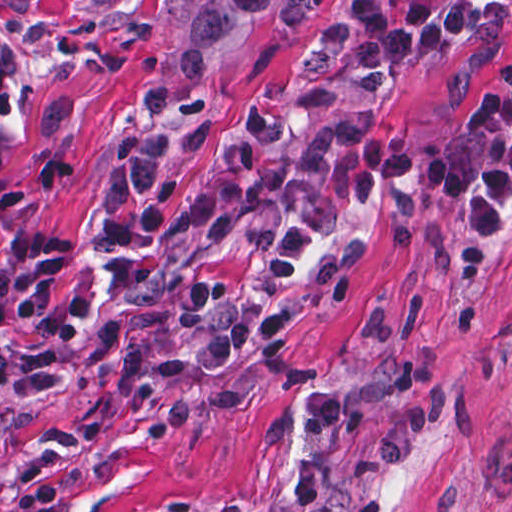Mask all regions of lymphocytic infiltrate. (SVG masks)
Returning <instances> with one entry per match:
<instances>
[{"instance_id":"f902f5d3","label":"lymphocytic infiltrate","mask_w":512,"mask_h":512,"mask_svg":"<svg viewBox=\"0 0 512 512\" xmlns=\"http://www.w3.org/2000/svg\"><path fill=\"white\" fill-rule=\"evenodd\" d=\"M493 0H349L335 27L301 70L292 103L255 99L195 178L180 211V231L255 234L269 239L265 270L235 296L231 274L205 265L181 268L185 322L200 332L189 356L196 374L219 369L266 346L268 330L305 276L314 244L361 222L391 201L414 198L468 212L477 248L512 240V53L500 86L484 93L467 124L418 139L372 130L331 145H305V130L353 92L411 59L477 32ZM18 114V87L0 70V153ZM171 181L157 183L133 216L100 223L109 248H134L166 224ZM73 243L16 235L14 258L28 273L0 266V397L42 394L65 368V349L112 358V322L82 334L90 315L77 297L63 319L53 295Z\"/></svg>"}]
</instances>
